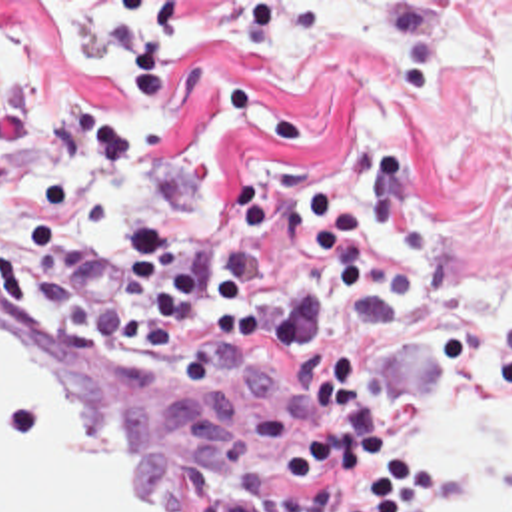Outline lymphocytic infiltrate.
I'll list each match as a JSON object with an SVG mask.
<instances>
[{"label": "lymphocytic infiltrate", "instance_id": "lymphocytic-infiltrate-1", "mask_svg": "<svg viewBox=\"0 0 512 512\" xmlns=\"http://www.w3.org/2000/svg\"><path fill=\"white\" fill-rule=\"evenodd\" d=\"M131 164V138L81 112L55 118L43 136L41 172L27 242L61 274L79 276L109 260L125 270L127 303L115 343L161 349L187 321H205L203 349L267 341L273 357L325 389L313 437L283 455L281 479L301 487L293 512H415L437 497V471L407 459L383 423L351 357L317 343L321 292L345 305L367 294L365 226L341 194L315 192L301 220L295 266L285 286L265 280L275 224L273 186L245 194V240L213 266H185L161 226H135L123 244L99 242L85 226L99 174Z\"/></svg>", "mask_w": 512, "mask_h": 512}]
</instances>
